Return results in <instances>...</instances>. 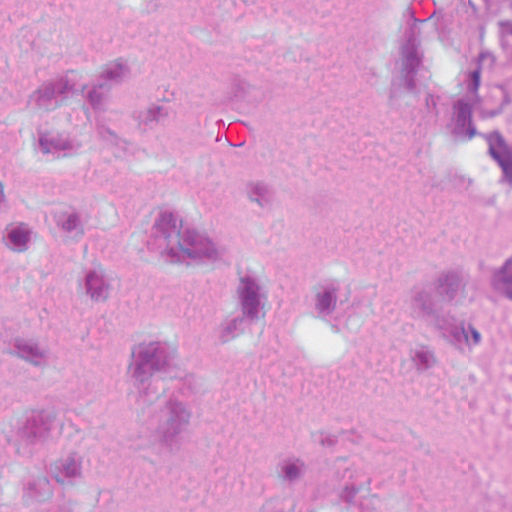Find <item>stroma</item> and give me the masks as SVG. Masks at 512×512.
I'll return each instance as SVG.
<instances>
[{
  "label": "stroma",
  "mask_w": 512,
  "mask_h": 512,
  "mask_svg": "<svg viewBox=\"0 0 512 512\" xmlns=\"http://www.w3.org/2000/svg\"><path fill=\"white\" fill-rule=\"evenodd\" d=\"M446 234L449 286L486 258L512 254V189L488 184L429 135ZM452 512L512 509V350L449 348Z\"/></svg>",
  "instance_id": "35a3bbf8"
}]
</instances>
